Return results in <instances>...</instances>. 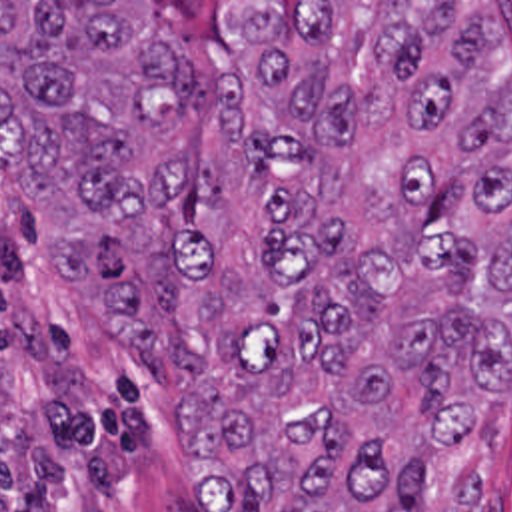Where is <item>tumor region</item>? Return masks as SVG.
Segmentation results:
<instances>
[{"label":"tumor region","mask_w":512,"mask_h":512,"mask_svg":"<svg viewBox=\"0 0 512 512\" xmlns=\"http://www.w3.org/2000/svg\"><path fill=\"white\" fill-rule=\"evenodd\" d=\"M0 2V170L108 341L180 371L194 512H493L438 495L512 375V76L491 2ZM22 512H68L56 489Z\"/></svg>","instance_id":"1"}]
</instances>
